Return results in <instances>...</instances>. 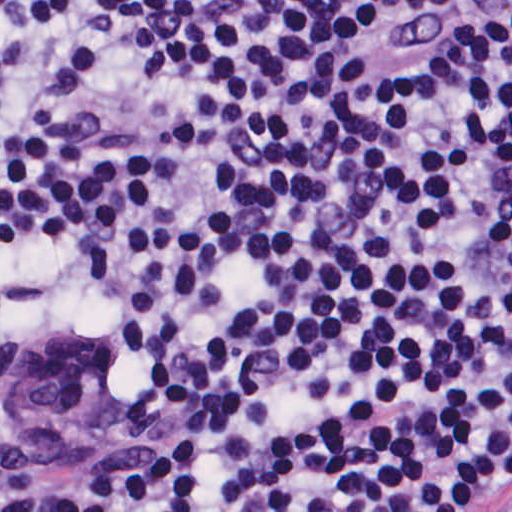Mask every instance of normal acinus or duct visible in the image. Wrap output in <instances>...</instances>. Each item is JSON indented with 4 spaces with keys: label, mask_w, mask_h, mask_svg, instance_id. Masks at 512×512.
<instances>
[{
    "label": "normal acinus or duct",
    "mask_w": 512,
    "mask_h": 512,
    "mask_svg": "<svg viewBox=\"0 0 512 512\" xmlns=\"http://www.w3.org/2000/svg\"><path fill=\"white\" fill-rule=\"evenodd\" d=\"M1 396L33 452L113 446L141 434L142 398L119 371L84 351L63 355L9 340L1 349Z\"/></svg>",
    "instance_id": "1"
}]
</instances>
